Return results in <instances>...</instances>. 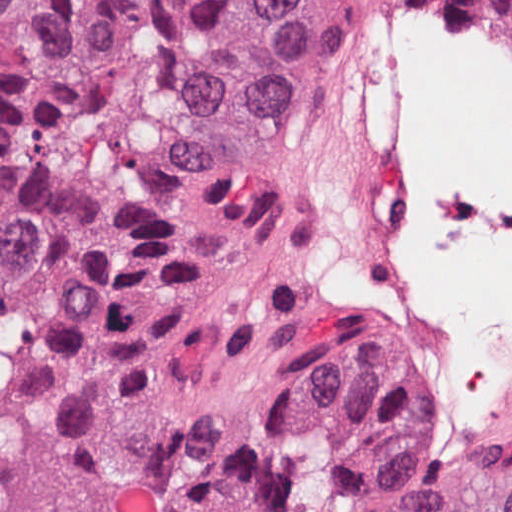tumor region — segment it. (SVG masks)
<instances>
[{
	"mask_svg": "<svg viewBox=\"0 0 512 512\" xmlns=\"http://www.w3.org/2000/svg\"><path fill=\"white\" fill-rule=\"evenodd\" d=\"M512 35V0H471ZM404 0H0V512H512V421L312 315L302 178Z\"/></svg>",
	"mask_w": 512,
	"mask_h": 512,
	"instance_id": "1",
	"label": "tumor region"
}]
</instances>
